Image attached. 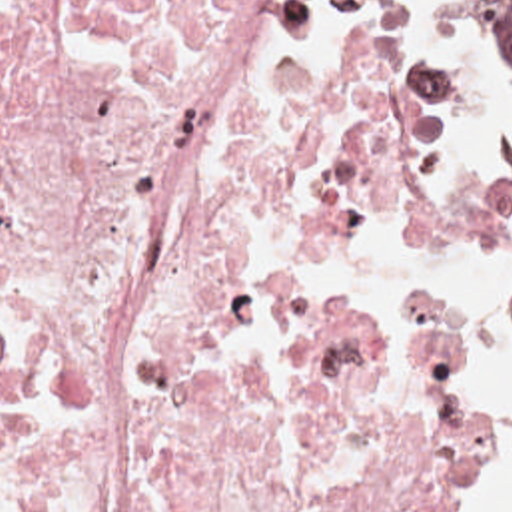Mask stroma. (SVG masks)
Instances as JSON below:
<instances>
[{
	"instance_id": "stroma-1",
	"label": "stroma",
	"mask_w": 512,
	"mask_h": 512,
	"mask_svg": "<svg viewBox=\"0 0 512 512\" xmlns=\"http://www.w3.org/2000/svg\"><path fill=\"white\" fill-rule=\"evenodd\" d=\"M379 37V71L397 101L431 113L445 179L475 189L455 217H419L385 207L361 185L319 193L297 203L291 233V273L319 299L345 309H421L487 323L499 344L512 319V241L503 263L489 275L481 295H421L409 301H363L331 281L323 265V239L363 221H385L399 237L421 249L481 251L512 225V173L451 171L447 149L459 129L473 121L467 89L421 65L409 27V3L393 0H315ZM483 57L512 83V59L495 51L475 19L471 0H449ZM512 450V434L493 426L489 446L469 474L463 512H485Z\"/></svg>"
}]
</instances>
